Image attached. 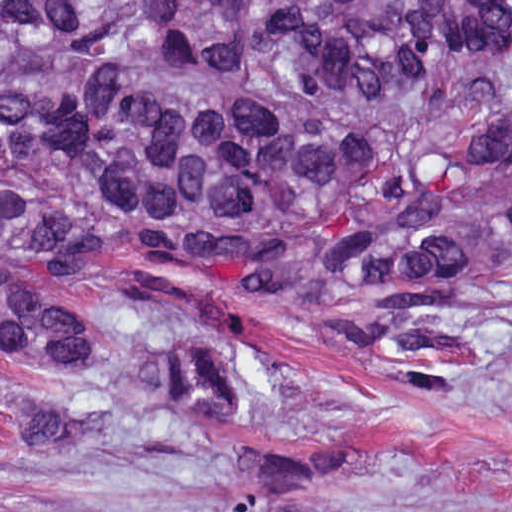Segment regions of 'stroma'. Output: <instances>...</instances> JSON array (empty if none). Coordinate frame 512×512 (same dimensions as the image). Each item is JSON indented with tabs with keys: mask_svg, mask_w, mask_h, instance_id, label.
<instances>
[{
	"mask_svg": "<svg viewBox=\"0 0 512 512\" xmlns=\"http://www.w3.org/2000/svg\"><path fill=\"white\" fill-rule=\"evenodd\" d=\"M0 1H512V0H0ZM512 194V162L473 184L467 198ZM4 265L82 305L129 286L198 305L254 343L269 368L290 367L270 388L255 427L235 444L190 440L163 426H119L93 449H54L0 433V512L85 507L161 512L209 494L243 444L349 431L359 459L344 496L460 509L512 498V339L480 372L436 396L400 388L355 352L314 336L315 304L237 289L155 261L130 233L79 273L50 260L4 256ZM42 393L44 381L0 359V393ZM0 414V431L12 424Z\"/></svg>",
	"mask_w": 512,
	"mask_h": 512,
	"instance_id": "35a3bbf8",
	"label": "stroma"
}]
</instances>
